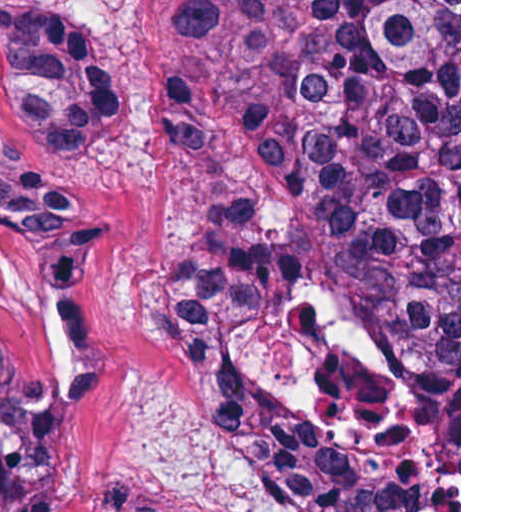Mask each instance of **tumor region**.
<instances>
[{
  "mask_svg": "<svg viewBox=\"0 0 512 512\" xmlns=\"http://www.w3.org/2000/svg\"><path fill=\"white\" fill-rule=\"evenodd\" d=\"M77 1H0L18 119L79 166L121 119ZM250 122L277 186L186 240L162 321L223 440L294 512H459V1H187L164 87L202 161ZM0 512H71L0 354ZM101 512H196L119 480Z\"/></svg>",
  "mask_w": 512,
  "mask_h": 512,
  "instance_id": "tumor-region-1",
  "label": "tumor region"
}]
</instances>
